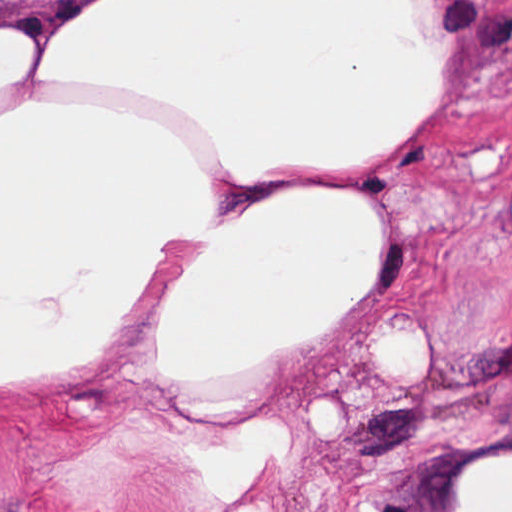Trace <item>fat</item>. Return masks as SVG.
<instances>
[{"label": "fat", "mask_w": 512, "mask_h": 512, "mask_svg": "<svg viewBox=\"0 0 512 512\" xmlns=\"http://www.w3.org/2000/svg\"><path fill=\"white\" fill-rule=\"evenodd\" d=\"M452 91L431 0H85L39 45L0 16V101L19 98L0 112V392L102 359L155 281L144 359L183 399L219 404L284 366L372 283L379 218L324 185L244 204L218 191L378 162ZM490 147L472 149L479 176L502 170ZM376 357L409 379L408 320L376 335ZM262 420L216 465L218 496L251 489L282 443ZM320 422L340 433L327 398ZM458 498L512 512V459L476 463Z\"/></svg>", "instance_id": "obj_1"}]
</instances>
